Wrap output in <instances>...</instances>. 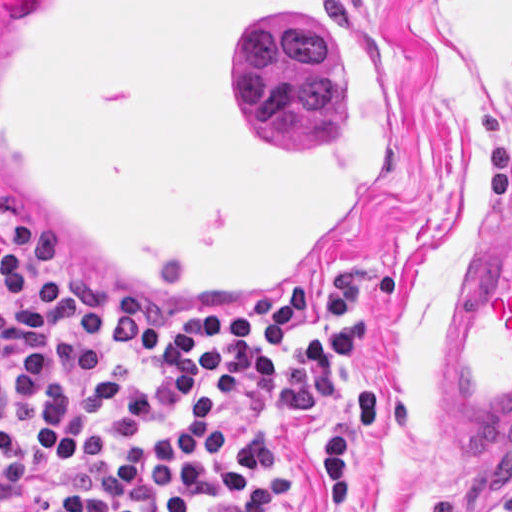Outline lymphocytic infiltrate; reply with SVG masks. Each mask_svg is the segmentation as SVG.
Masks as SVG:
<instances>
[{
	"mask_svg": "<svg viewBox=\"0 0 512 512\" xmlns=\"http://www.w3.org/2000/svg\"><path fill=\"white\" fill-rule=\"evenodd\" d=\"M394 304L384 272L270 316H179L86 283L3 215L0 512H278L280 441L321 418L327 510L364 512L354 438L380 445L392 399L353 367Z\"/></svg>",
	"mask_w": 512,
	"mask_h": 512,
	"instance_id": "lymphocytic-infiltrate-1",
	"label": "lymphocytic infiltrate"
}]
</instances>
